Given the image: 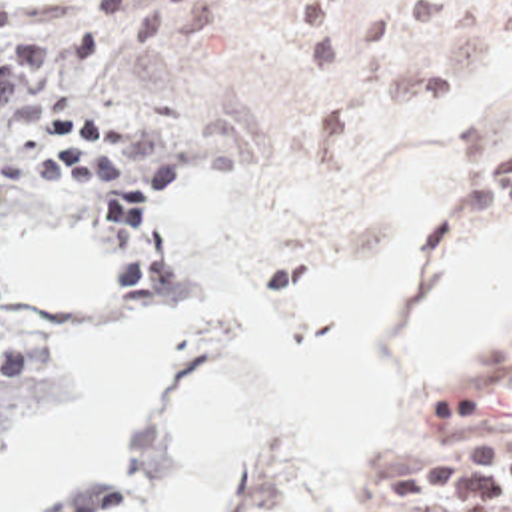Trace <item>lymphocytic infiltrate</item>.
<instances>
[{
  "label": "lymphocytic infiltrate",
  "instance_id": "obj_1",
  "mask_svg": "<svg viewBox=\"0 0 512 512\" xmlns=\"http://www.w3.org/2000/svg\"><path fill=\"white\" fill-rule=\"evenodd\" d=\"M90 0L82 8L30 18L0 4V142L44 122L54 156L42 180H100L117 236L139 234L179 178L173 150L155 168L119 160L121 134L111 118L66 110L74 94L54 84L70 66L117 48H179L213 28L219 0ZM115 214V218H113ZM58 394V364L32 312L0 270V444Z\"/></svg>",
  "mask_w": 512,
  "mask_h": 512
}]
</instances>
